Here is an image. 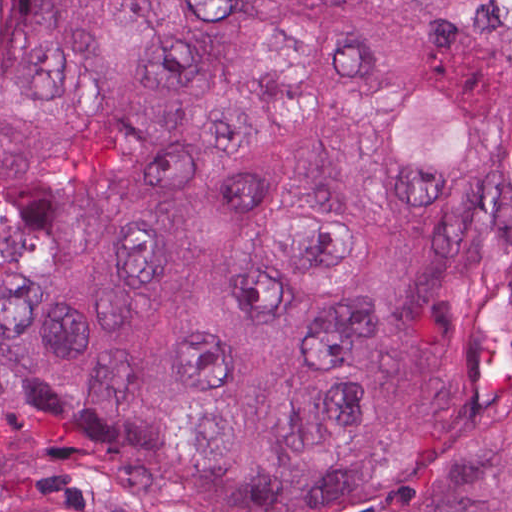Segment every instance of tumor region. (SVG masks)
<instances>
[{
  "mask_svg": "<svg viewBox=\"0 0 512 512\" xmlns=\"http://www.w3.org/2000/svg\"><path fill=\"white\" fill-rule=\"evenodd\" d=\"M0 512H512V0H0Z\"/></svg>",
  "mask_w": 512,
  "mask_h": 512,
  "instance_id": "obj_1",
  "label": "tumor region"
}]
</instances>
